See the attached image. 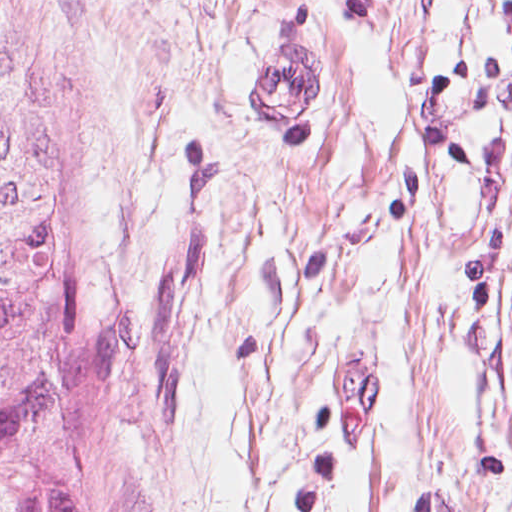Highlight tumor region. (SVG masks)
<instances>
[{"label": "tumor region", "mask_w": 512, "mask_h": 512, "mask_svg": "<svg viewBox=\"0 0 512 512\" xmlns=\"http://www.w3.org/2000/svg\"><path fill=\"white\" fill-rule=\"evenodd\" d=\"M49 25L0 0V512H139Z\"/></svg>", "instance_id": "tumor-region-1"}]
</instances>
